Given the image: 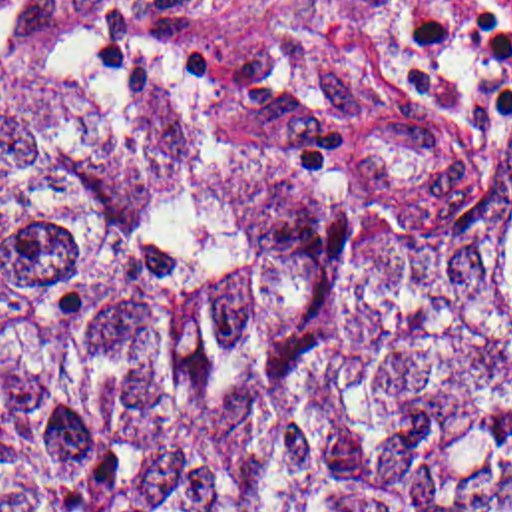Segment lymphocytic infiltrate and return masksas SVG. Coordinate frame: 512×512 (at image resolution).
Instances as JSON below:
<instances>
[{
  "label": "lymphocytic infiltrate",
  "mask_w": 512,
  "mask_h": 512,
  "mask_svg": "<svg viewBox=\"0 0 512 512\" xmlns=\"http://www.w3.org/2000/svg\"><path fill=\"white\" fill-rule=\"evenodd\" d=\"M398 79L447 125H481L512 95V0H412Z\"/></svg>",
  "instance_id": "f902f5d3"
}]
</instances>
